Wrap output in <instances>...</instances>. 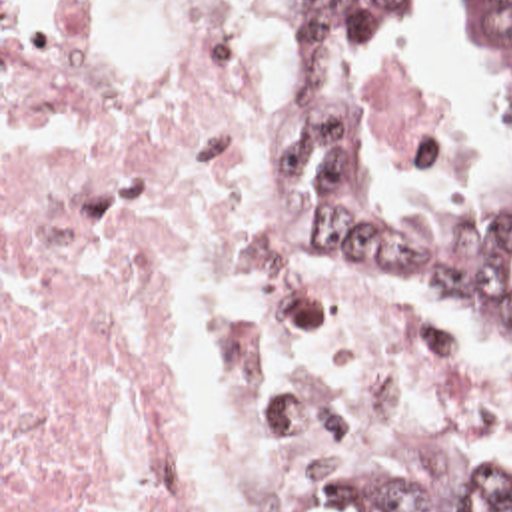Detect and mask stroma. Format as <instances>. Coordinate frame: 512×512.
<instances>
[{
    "mask_svg": "<svg viewBox=\"0 0 512 512\" xmlns=\"http://www.w3.org/2000/svg\"><path fill=\"white\" fill-rule=\"evenodd\" d=\"M64 0H0V512H2V6L48 8ZM455 0H403L397 12L391 52L373 66H419L429 40H449V12ZM373 66H321L300 62V74L270 120L262 142L266 164L298 114L313 100L327 96L341 100L355 122L361 156L377 178L387 206L413 230L425 236H475L493 228L507 212V146L503 126L491 96V180L489 188L467 198H411L389 180L367 140L361 102ZM429 70V68H421ZM315 256V254H313ZM317 264L353 298L367 308L423 328L491 380L512 412V364L481 342L473 322L453 316L437 298L399 290L361 266H335L319 256ZM347 456H417L429 464L465 473H512V456L497 462L459 456L433 442H367ZM325 477V475H323ZM317 485L300 512H313Z\"/></svg>",
    "mask_w": 512,
    "mask_h": 512,
    "instance_id": "35a3bbf8",
    "label": "stroma"
}]
</instances>
